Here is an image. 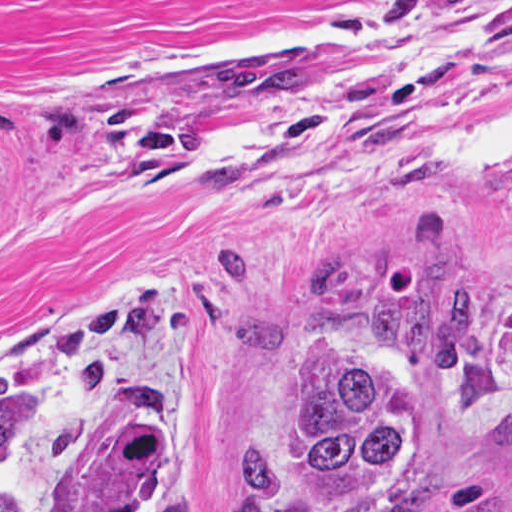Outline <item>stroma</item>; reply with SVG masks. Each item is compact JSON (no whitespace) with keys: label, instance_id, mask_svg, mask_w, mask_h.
Returning a JSON list of instances; mask_svg holds the SVG:
<instances>
[{"label":"stroma","instance_id":"35a3bbf8","mask_svg":"<svg viewBox=\"0 0 512 512\" xmlns=\"http://www.w3.org/2000/svg\"><path fill=\"white\" fill-rule=\"evenodd\" d=\"M307 53V93L225 90L223 60ZM512 81V0H0V386L56 381L53 446L5 512H84L117 419L65 324L153 286L162 317L100 358L162 401L160 493L243 512L317 343L412 268L486 295L451 448L364 512H512V184L445 126ZM152 512V509L151 511Z\"/></svg>","mask_w":512,"mask_h":512}]
</instances>
